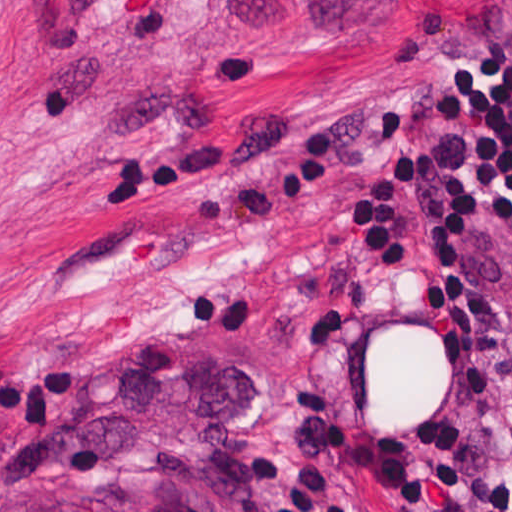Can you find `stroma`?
<instances>
[{"instance_id":"stroma-1","label":"stroma","mask_w":512,"mask_h":512,"mask_svg":"<svg viewBox=\"0 0 512 512\" xmlns=\"http://www.w3.org/2000/svg\"><path fill=\"white\" fill-rule=\"evenodd\" d=\"M465 47L512 56V0H0V485L75 368L166 328L252 360L225 455L274 512H453L379 463L449 391L426 200L420 279L355 247L342 183L379 113L452 146L420 94ZM473 276L512 356V232ZM490 398L476 459L512 470Z\"/></svg>"}]
</instances>
